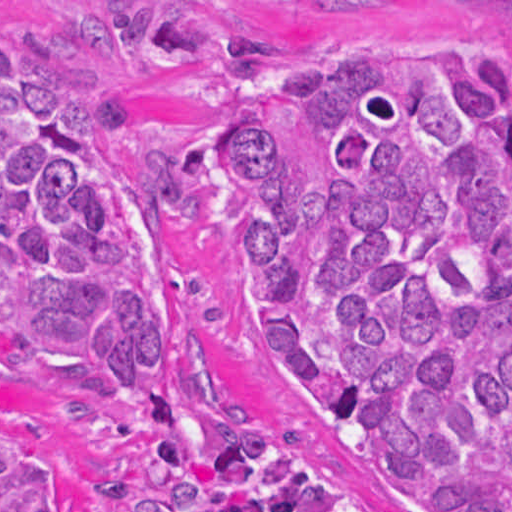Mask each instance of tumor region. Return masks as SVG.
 Masks as SVG:
<instances>
[{"instance_id":"tumor-region-1","label":"tumor region","mask_w":512,"mask_h":512,"mask_svg":"<svg viewBox=\"0 0 512 512\" xmlns=\"http://www.w3.org/2000/svg\"><path fill=\"white\" fill-rule=\"evenodd\" d=\"M93 60L0 36V327L74 359L84 418L147 430L161 512H512V57L446 39L281 59L236 39L217 140L259 216V348L307 427L195 409L182 293L123 263L140 149ZM0 512H56L0 434Z\"/></svg>"}]
</instances>
